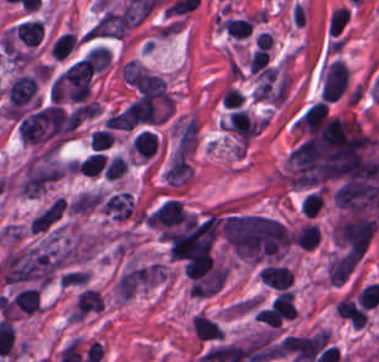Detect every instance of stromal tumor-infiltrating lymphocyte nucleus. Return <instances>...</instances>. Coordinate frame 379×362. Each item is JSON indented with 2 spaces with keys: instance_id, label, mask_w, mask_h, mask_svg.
I'll return each instance as SVG.
<instances>
[{
  "instance_id": "bc302bb0",
  "label": "stromal tumor-infiltrating lymphocyte nucleus",
  "mask_w": 379,
  "mask_h": 362,
  "mask_svg": "<svg viewBox=\"0 0 379 362\" xmlns=\"http://www.w3.org/2000/svg\"><path fill=\"white\" fill-rule=\"evenodd\" d=\"M376 225L377 220L355 213L339 218L333 234L351 254L361 258L375 232Z\"/></svg>"
},
{
  "instance_id": "52c7bb5b",
  "label": "stromal tumor-infiltrating lymphocyte nucleus",
  "mask_w": 379,
  "mask_h": 362,
  "mask_svg": "<svg viewBox=\"0 0 379 362\" xmlns=\"http://www.w3.org/2000/svg\"><path fill=\"white\" fill-rule=\"evenodd\" d=\"M294 124L309 138L323 144L326 128L325 102L319 99L304 109Z\"/></svg>"
},
{
  "instance_id": "3290ff9b",
  "label": "stromal tumor-infiltrating lymphocyte nucleus",
  "mask_w": 379,
  "mask_h": 362,
  "mask_svg": "<svg viewBox=\"0 0 379 362\" xmlns=\"http://www.w3.org/2000/svg\"><path fill=\"white\" fill-rule=\"evenodd\" d=\"M103 306L104 302L101 292L87 287L76 295L71 319H82L103 309Z\"/></svg>"
},
{
  "instance_id": "abfb95fc",
  "label": "stromal tumor-infiltrating lymphocyte nucleus",
  "mask_w": 379,
  "mask_h": 362,
  "mask_svg": "<svg viewBox=\"0 0 379 362\" xmlns=\"http://www.w3.org/2000/svg\"><path fill=\"white\" fill-rule=\"evenodd\" d=\"M186 210L179 200L167 199L153 213L150 223L153 226H174L185 221Z\"/></svg>"
},
{
  "instance_id": "9ea309e8",
  "label": "stromal tumor-infiltrating lymphocyte nucleus",
  "mask_w": 379,
  "mask_h": 362,
  "mask_svg": "<svg viewBox=\"0 0 379 362\" xmlns=\"http://www.w3.org/2000/svg\"><path fill=\"white\" fill-rule=\"evenodd\" d=\"M294 276V271L284 264L269 263L261 269L260 278L267 285L279 289L289 288Z\"/></svg>"
},
{
  "instance_id": "f3e2335f",
  "label": "stromal tumor-infiltrating lymphocyte nucleus",
  "mask_w": 379,
  "mask_h": 362,
  "mask_svg": "<svg viewBox=\"0 0 379 362\" xmlns=\"http://www.w3.org/2000/svg\"><path fill=\"white\" fill-rule=\"evenodd\" d=\"M134 205L132 192L121 191L108 196L104 205L103 212L117 218L129 217Z\"/></svg>"
},
{
  "instance_id": "4f13568d",
  "label": "stromal tumor-infiltrating lymphocyte nucleus",
  "mask_w": 379,
  "mask_h": 362,
  "mask_svg": "<svg viewBox=\"0 0 379 362\" xmlns=\"http://www.w3.org/2000/svg\"><path fill=\"white\" fill-rule=\"evenodd\" d=\"M272 312L279 320L290 319L296 314L295 298L292 290L283 289L274 299Z\"/></svg>"
},
{
  "instance_id": "2a367800",
  "label": "stromal tumor-infiltrating lymphocyte nucleus",
  "mask_w": 379,
  "mask_h": 362,
  "mask_svg": "<svg viewBox=\"0 0 379 362\" xmlns=\"http://www.w3.org/2000/svg\"><path fill=\"white\" fill-rule=\"evenodd\" d=\"M192 328L200 340L218 338L223 332L216 322L203 314H197L191 321Z\"/></svg>"
},
{
  "instance_id": "4803ca6d",
  "label": "stromal tumor-infiltrating lymphocyte nucleus",
  "mask_w": 379,
  "mask_h": 362,
  "mask_svg": "<svg viewBox=\"0 0 379 362\" xmlns=\"http://www.w3.org/2000/svg\"><path fill=\"white\" fill-rule=\"evenodd\" d=\"M292 239L302 249H313L319 240L318 226L307 223L297 230Z\"/></svg>"
},
{
  "instance_id": "4245b91a",
  "label": "stromal tumor-infiltrating lymphocyte nucleus",
  "mask_w": 379,
  "mask_h": 362,
  "mask_svg": "<svg viewBox=\"0 0 379 362\" xmlns=\"http://www.w3.org/2000/svg\"><path fill=\"white\" fill-rule=\"evenodd\" d=\"M132 149L142 156H151L155 152L156 134L147 130H140L131 143Z\"/></svg>"
},
{
  "instance_id": "4c9ddf68",
  "label": "stromal tumor-infiltrating lymphocyte nucleus",
  "mask_w": 379,
  "mask_h": 362,
  "mask_svg": "<svg viewBox=\"0 0 379 362\" xmlns=\"http://www.w3.org/2000/svg\"><path fill=\"white\" fill-rule=\"evenodd\" d=\"M114 134L106 128H98L92 132L90 146L103 149L112 144Z\"/></svg>"
}]
</instances>
